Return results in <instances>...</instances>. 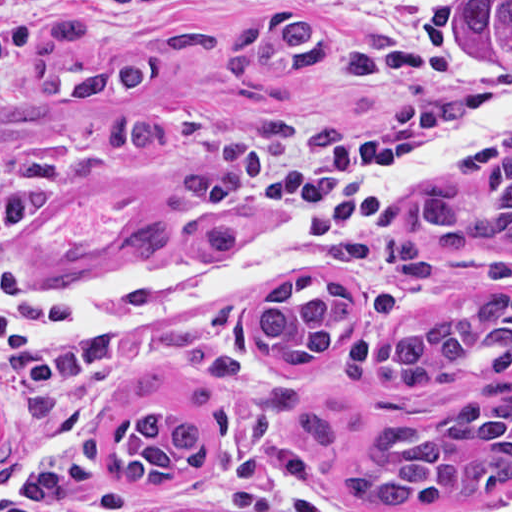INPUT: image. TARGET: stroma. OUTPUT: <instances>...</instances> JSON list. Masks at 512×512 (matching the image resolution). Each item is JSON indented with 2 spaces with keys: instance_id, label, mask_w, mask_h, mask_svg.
<instances>
[{
  "instance_id": "obj_1",
  "label": "stroma",
  "mask_w": 512,
  "mask_h": 512,
  "mask_svg": "<svg viewBox=\"0 0 512 512\" xmlns=\"http://www.w3.org/2000/svg\"><path fill=\"white\" fill-rule=\"evenodd\" d=\"M66 1L0 0V97L30 89L27 54ZM281 14L306 16L341 39L404 45L417 57V73L368 82L301 70L251 83L230 79L217 63L187 60L146 91L96 105L72 98L63 106L151 111L214 165L222 126L254 118L300 136L320 130L371 138L401 160L496 77L458 74L409 34L333 16L319 0H173L150 15L98 22L84 38L125 44L189 17L239 29ZM509 133L512 121L498 123L468 151ZM459 155L406 196L437 183L473 186L454 170ZM228 183L240 233L286 215L268 196ZM0 193L20 203L0 250L1 276L59 287L107 279L143 259L124 251L125 236L193 192L169 176L160 157L105 148L95 137L64 142L40 133L0 143ZM179 255L187 254L175 249L152 257ZM431 267L432 276L396 272L382 252L375 264L307 265L249 280L175 317L113 325L95 339L50 334L65 346L87 348L95 360L63 386L19 383L0 360V512H512V486L480 493L459 509L355 504L341 483L340 461L310 443L293 415L297 408L316 412L343 446L360 452L373 441L375 420L425 424L489 385L512 387V378L482 380L476 366L444 381L372 382L369 363L381 341L468 288L512 290V251L478 241L448 251ZM298 272L337 282L361 306L362 323L342 352L279 363L257 345L256 317L273 285ZM141 409L204 428L206 465L154 486L110 478L113 429Z\"/></svg>"
}]
</instances>
